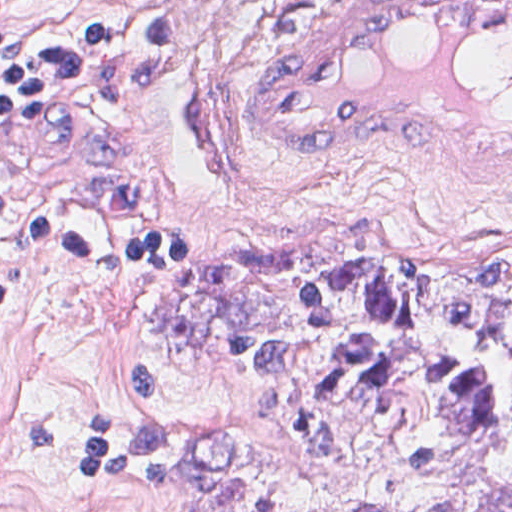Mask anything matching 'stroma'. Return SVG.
I'll use <instances>...</instances> for the list:
<instances>
[{"instance_id":"stroma-1","label":"stroma","mask_w":512,"mask_h":512,"mask_svg":"<svg viewBox=\"0 0 512 512\" xmlns=\"http://www.w3.org/2000/svg\"><path fill=\"white\" fill-rule=\"evenodd\" d=\"M0 1H69L77 14L159 8L175 38L152 61L0 131V172L189 241L182 265L101 269L0 238V512H445L512 468V358L480 329L294 319L171 341L146 317L159 284L285 245L334 248L369 271L481 274L512 262V190L446 179L415 155L273 153L242 122L286 1L512 0ZM325 332L480 354L495 370V440L393 494L308 454L289 425L266 423L256 402L265 380L213 349L236 335Z\"/></svg>"}]
</instances>
